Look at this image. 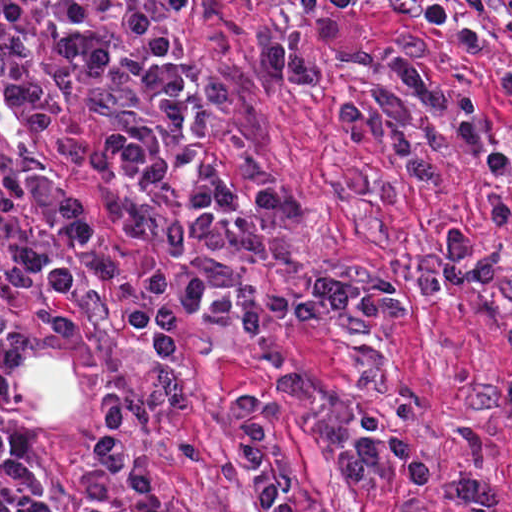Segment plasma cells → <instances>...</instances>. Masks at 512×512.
<instances>
[{
  "label": "plasma cells",
  "instance_id": "1",
  "mask_svg": "<svg viewBox=\"0 0 512 512\" xmlns=\"http://www.w3.org/2000/svg\"><path fill=\"white\" fill-rule=\"evenodd\" d=\"M462 4L463 12H457L445 0H391L382 9L445 33L466 54L487 49V38L475 26L488 18L512 40V1ZM321 52L395 73L437 116L420 119L384 88L337 113L351 145L391 144L410 182L439 184L447 151L442 128L454 124L466 154L492 178L483 257L474 258L471 229L462 226L449 230L435 258L417 259L419 274L408 285L332 275L295 296L264 286L243 288L233 297L210 296L218 270L251 237H278L281 203L275 194H246L226 168H209L188 187L181 174L191 105L187 54L164 30L114 1H1V93L54 143L77 158L107 165L96 192L67 187L42 171L28 173L40 227L70 250H43L0 234V283L32 292L56 334L78 331L75 291L87 265L102 279L119 272L100 230L105 216L117 219L133 244L159 260L157 277L119 310L122 324L159 356L176 352V320L186 311L196 310L203 322L242 328L255 367L286 401L305 399V383L285 365L271 322L354 313L407 320L417 302L436 298L446 286L490 288L501 275L496 234L512 228L503 192L512 174V134L499 152L486 145L477 94L425 72L418 38H403L394 53H384L338 19L313 21L297 47L271 40L256 77L316 90L323 82L316 64ZM496 94L512 102V76L499 83ZM505 411L512 413V385L459 423L456 443L466 471L453 499L461 512H499L497 492L475 476L483 457L476 423ZM0 496L16 512H55L31 464L30 441L12 428L0 429ZM317 512L340 511L323 506Z\"/></svg>",
  "mask_w": 512,
  "mask_h": 512
}]
</instances>
